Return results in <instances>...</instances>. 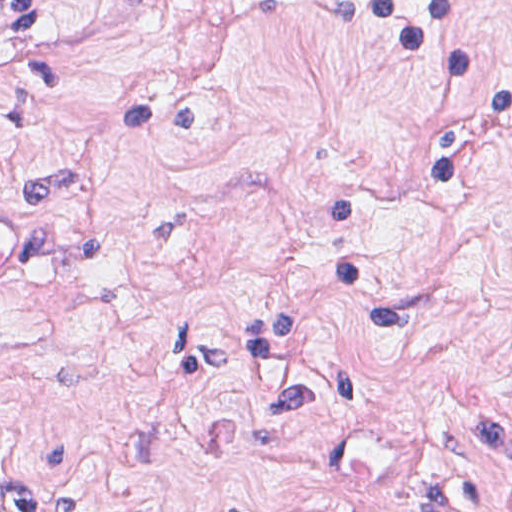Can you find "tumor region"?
I'll list each match as a JSON object with an SVG mask.
<instances>
[{
  "label": "tumor region",
  "mask_w": 512,
  "mask_h": 512,
  "mask_svg": "<svg viewBox=\"0 0 512 512\" xmlns=\"http://www.w3.org/2000/svg\"><path fill=\"white\" fill-rule=\"evenodd\" d=\"M58 20V0H0V26L15 33L52 39Z\"/></svg>",
  "instance_id": "tumor-region-1"
}]
</instances>
